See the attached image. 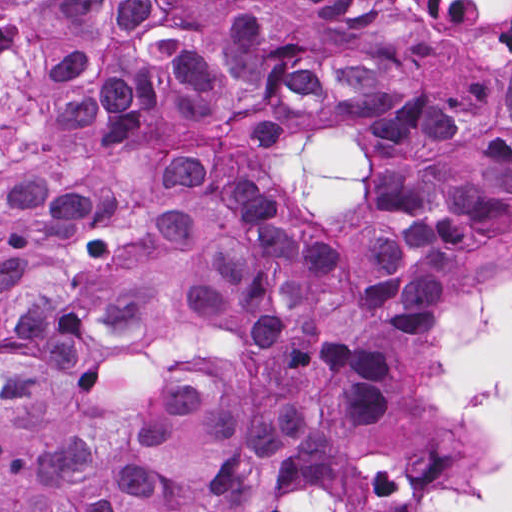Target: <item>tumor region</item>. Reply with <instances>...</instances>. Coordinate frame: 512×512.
Returning <instances> with one entry per match:
<instances>
[{
  "label": "tumor region",
  "mask_w": 512,
  "mask_h": 512,
  "mask_svg": "<svg viewBox=\"0 0 512 512\" xmlns=\"http://www.w3.org/2000/svg\"><path fill=\"white\" fill-rule=\"evenodd\" d=\"M338 67L331 118L389 144L351 245L291 234L230 159L322 79L252 15L128 88L108 229L47 183L0 192V512H433L458 436L400 359L512 244V73L420 108L410 68Z\"/></svg>",
  "instance_id": "tumor-region-1"
}]
</instances>
